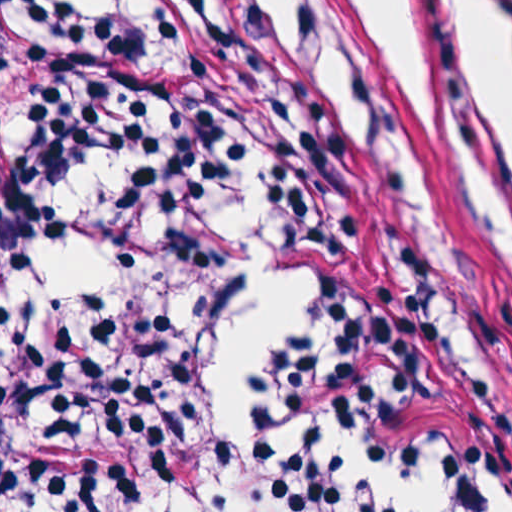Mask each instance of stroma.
<instances>
[{"mask_svg": "<svg viewBox=\"0 0 512 512\" xmlns=\"http://www.w3.org/2000/svg\"><path fill=\"white\" fill-rule=\"evenodd\" d=\"M341 51L352 148L391 264L512 425V210L473 194L439 160L338 0H320ZM0 512L5 500L1 335Z\"/></svg>", "mask_w": 512, "mask_h": 512, "instance_id": "35a3bbf8", "label": "stroma"}]
</instances>
